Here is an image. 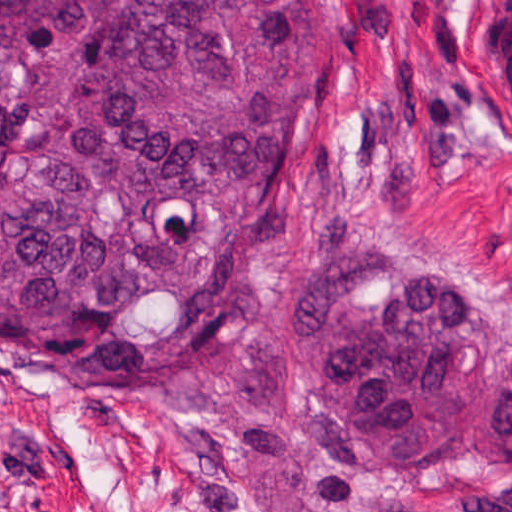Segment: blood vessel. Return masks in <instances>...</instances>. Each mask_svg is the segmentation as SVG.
<instances>
[{"label":"blood vessel","instance_id":"obj_1","mask_svg":"<svg viewBox=\"0 0 512 512\" xmlns=\"http://www.w3.org/2000/svg\"><path fill=\"white\" fill-rule=\"evenodd\" d=\"M483 63L487 85L512 123V0H504L486 25Z\"/></svg>","mask_w":512,"mask_h":512}]
</instances>
